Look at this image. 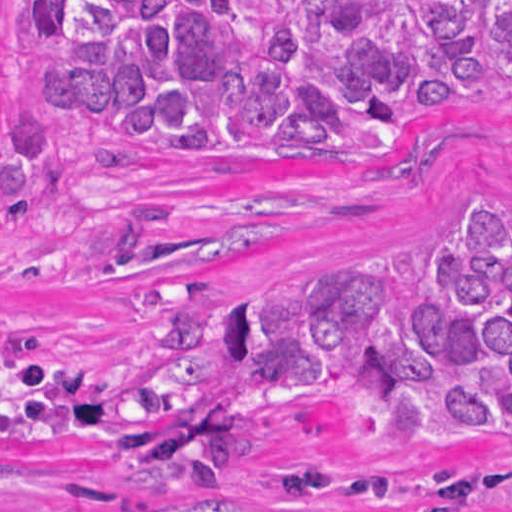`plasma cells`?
Returning <instances> with one entry per match:
<instances>
[{"mask_svg":"<svg viewBox=\"0 0 512 512\" xmlns=\"http://www.w3.org/2000/svg\"><path fill=\"white\" fill-rule=\"evenodd\" d=\"M0 512H13V510L0 506ZM69 512H118V511L96 510L94 504H75Z\"/></svg>","mask_w":512,"mask_h":512,"instance_id":"obj_1","label":"plasma cells"}]
</instances>
